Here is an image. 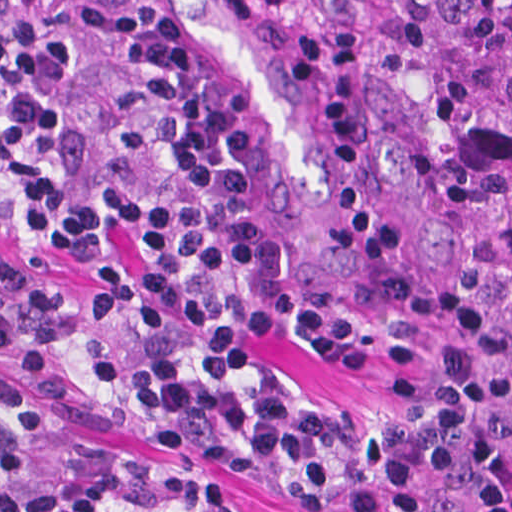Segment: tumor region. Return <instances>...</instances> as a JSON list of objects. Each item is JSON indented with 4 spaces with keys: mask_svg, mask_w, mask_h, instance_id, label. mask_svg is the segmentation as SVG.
Segmentation results:
<instances>
[{
    "mask_svg": "<svg viewBox=\"0 0 512 512\" xmlns=\"http://www.w3.org/2000/svg\"><path fill=\"white\" fill-rule=\"evenodd\" d=\"M350 40L438 112L485 229L480 290L512 320V0H350Z\"/></svg>",
    "mask_w": 512,
    "mask_h": 512,
    "instance_id": "1",
    "label": "tumor region"
}]
</instances>
